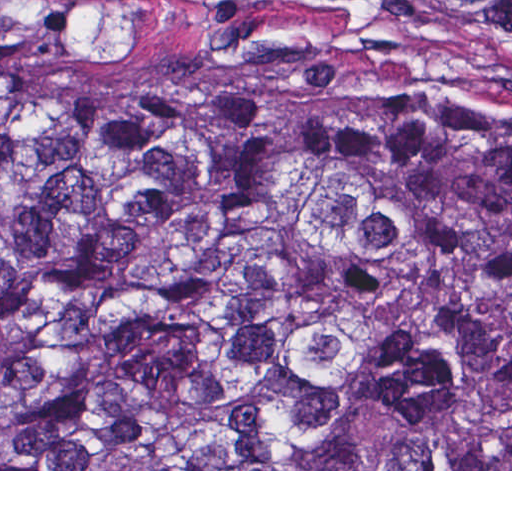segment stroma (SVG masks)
<instances>
[{
    "mask_svg": "<svg viewBox=\"0 0 512 512\" xmlns=\"http://www.w3.org/2000/svg\"><path fill=\"white\" fill-rule=\"evenodd\" d=\"M0 25L110 83L205 86L232 102L367 124L491 113L509 99L471 42L425 0H0Z\"/></svg>",
    "mask_w": 512,
    "mask_h": 512,
    "instance_id": "1",
    "label": "stroma"
}]
</instances>
